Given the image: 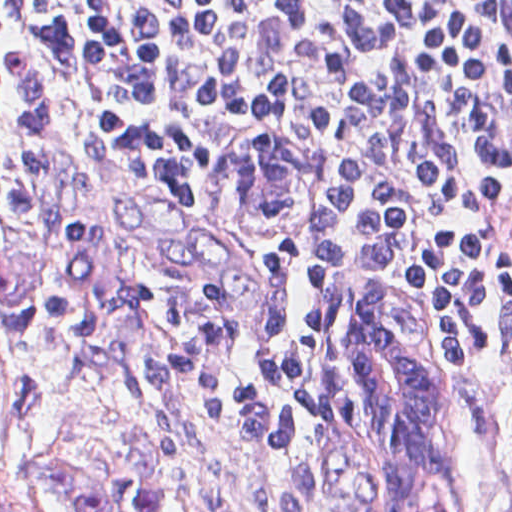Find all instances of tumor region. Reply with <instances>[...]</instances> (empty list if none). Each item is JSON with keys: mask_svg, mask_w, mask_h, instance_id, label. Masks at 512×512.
Instances as JSON below:
<instances>
[{"mask_svg": "<svg viewBox=\"0 0 512 512\" xmlns=\"http://www.w3.org/2000/svg\"><path fill=\"white\" fill-rule=\"evenodd\" d=\"M350 344L368 385L354 474L360 502L371 512H444L443 374L418 338L408 296L392 285L362 292ZM164 463V448L150 443L114 475L76 458L46 457L37 477L42 494L78 512H168Z\"/></svg>", "mask_w": 512, "mask_h": 512, "instance_id": "1", "label": "tumor region"}]
</instances>
